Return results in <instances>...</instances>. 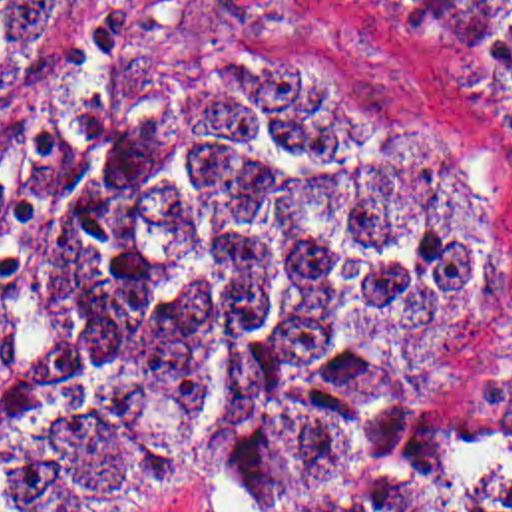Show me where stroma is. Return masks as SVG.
Here are the masks:
<instances>
[{
  "label": "stroma",
  "instance_id": "1",
  "mask_svg": "<svg viewBox=\"0 0 512 512\" xmlns=\"http://www.w3.org/2000/svg\"><path fill=\"white\" fill-rule=\"evenodd\" d=\"M196 50L309 52L381 149L425 155L501 197L473 293L419 360L429 426L512 448V81L451 58L401 0H82L78 38L49 89L0 99V402L23 348L35 257L96 155L102 115L138 77ZM124 512H250L232 480L154 474Z\"/></svg>",
  "mask_w": 512,
  "mask_h": 512
}]
</instances>
